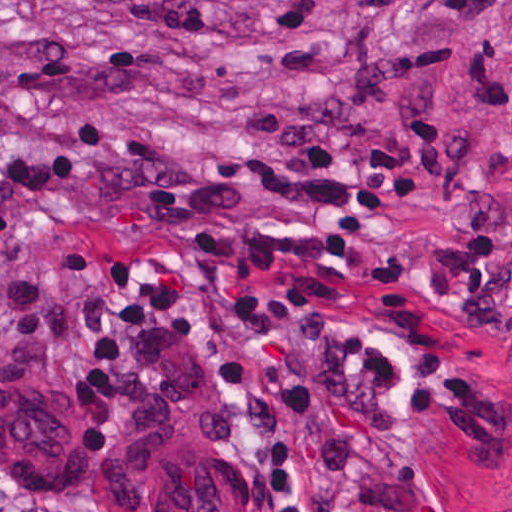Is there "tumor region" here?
<instances>
[{
  "mask_svg": "<svg viewBox=\"0 0 512 512\" xmlns=\"http://www.w3.org/2000/svg\"><path fill=\"white\" fill-rule=\"evenodd\" d=\"M95 512H240L224 485V436L187 369H153L127 421L88 451Z\"/></svg>",
  "mask_w": 512,
  "mask_h": 512,
  "instance_id": "obj_1",
  "label": "tumor region"
}]
</instances>
